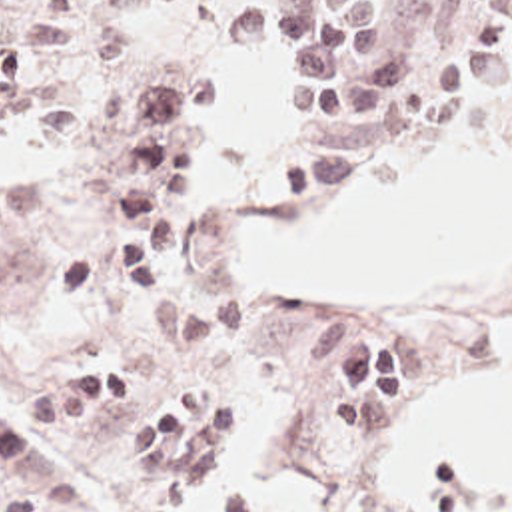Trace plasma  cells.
Here are the masks:
<instances>
[{"mask_svg":"<svg viewBox=\"0 0 512 512\" xmlns=\"http://www.w3.org/2000/svg\"><path fill=\"white\" fill-rule=\"evenodd\" d=\"M155 0H0V123L65 127L125 163L121 211L97 249L69 263L53 283L61 307H147L175 285L179 239L198 197L202 143L216 119V95L202 69L179 65L133 85L97 115L77 111L55 67L79 41L85 20L131 16ZM488 49L450 61L442 99H472L512 83V16L490 20ZM222 45L238 53L276 49L296 83L288 121L338 135L276 161L278 185H330L360 159L410 133L434 91V65L394 29V0L254 2L222 24ZM356 105L362 113L354 117ZM304 379L328 385L348 433L374 435L408 407V343L388 317L354 301L318 311L296 335ZM35 427H85L125 417L113 447L133 455L137 499L151 511L198 512L196 493L224 431L234 393L153 399L143 363H119L39 393L27 407ZM228 512H256L232 489ZM0 512H47L31 501H0Z\"/></svg>","mask_w":512,"mask_h":512,"instance_id":"9512152a","label":"plasma cells"}]
</instances>
